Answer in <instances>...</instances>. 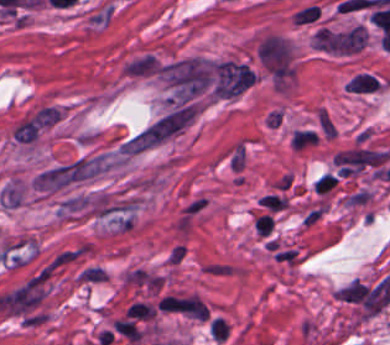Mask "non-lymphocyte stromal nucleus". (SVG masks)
I'll use <instances>...</instances> for the list:
<instances>
[{
	"instance_id": "dd21d789",
	"label": "non-lymphocyte stromal nucleus",
	"mask_w": 390,
	"mask_h": 345,
	"mask_svg": "<svg viewBox=\"0 0 390 345\" xmlns=\"http://www.w3.org/2000/svg\"><path fill=\"white\" fill-rule=\"evenodd\" d=\"M180 121L164 113L119 141L118 157L131 158L179 134Z\"/></svg>"
}]
</instances>
